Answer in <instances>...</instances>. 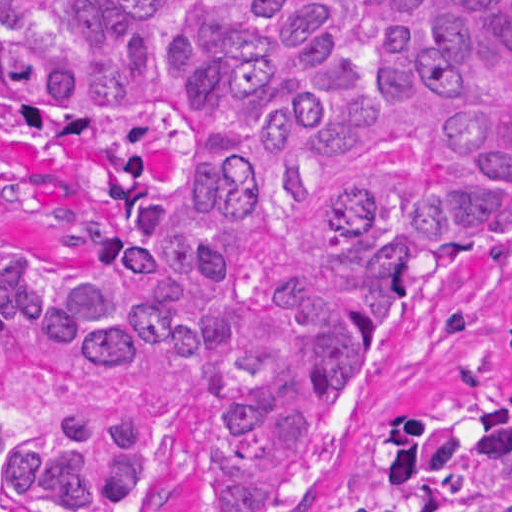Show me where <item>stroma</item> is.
I'll use <instances>...</instances> for the list:
<instances>
[{"mask_svg": "<svg viewBox=\"0 0 512 512\" xmlns=\"http://www.w3.org/2000/svg\"><path fill=\"white\" fill-rule=\"evenodd\" d=\"M191 151L166 113L112 123L1 118V240L80 245L109 178H169ZM512 391V238L470 272L405 296L369 348L356 395L307 434L286 463L285 512H385L405 483V419L463 395ZM218 446L208 419L182 417L152 490L129 512H209Z\"/></svg>", "mask_w": 512, "mask_h": 512, "instance_id": "1", "label": "stroma"}]
</instances>
